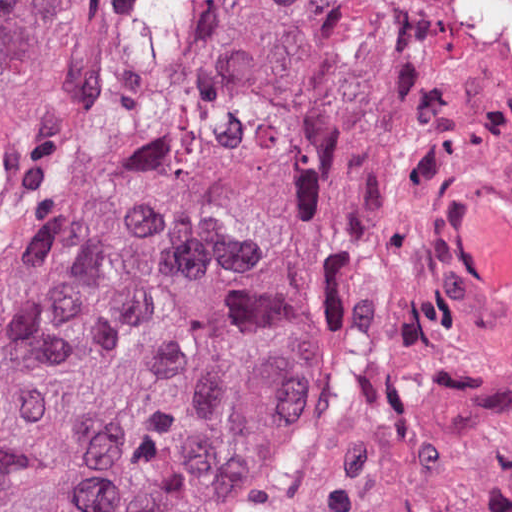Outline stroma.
I'll return each instance as SVG.
<instances>
[{"label":"stroma","instance_id":"obj_1","mask_svg":"<svg viewBox=\"0 0 512 512\" xmlns=\"http://www.w3.org/2000/svg\"><path fill=\"white\" fill-rule=\"evenodd\" d=\"M127 145L253 170L264 234L51 512H512V0H44L0 96V358Z\"/></svg>","mask_w":512,"mask_h":512}]
</instances>
